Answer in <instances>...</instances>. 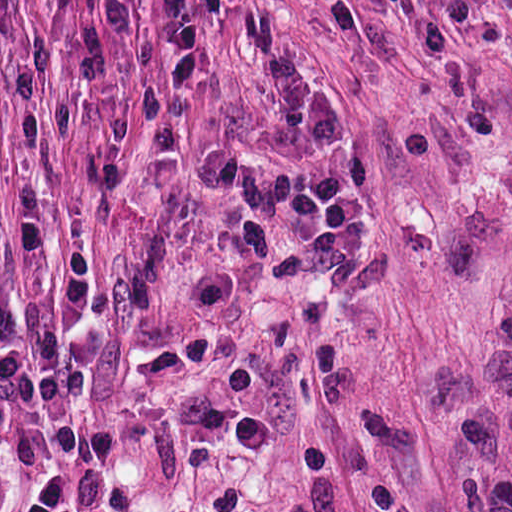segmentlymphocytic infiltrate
<instances>
[{
    "mask_svg": "<svg viewBox=\"0 0 512 512\" xmlns=\"http://www.w3.org/2000/svg\"><path fill=\"white\" fill-rule=\"evenodd\" d=\"M30 270L40 299L60 287V266L42 234L0 213V266ZM88 363L67 332L14 300L0 282V449L9 466L43 474L18 512H75L76 482L119 452L115 428L81 429L78 403Z\"/></svg>",
    "mask_w": 512,
    "mask_h": 512,
    "instance_id": "1",
    "label": "lymphocytic infiltrate"
}]
</instances>
